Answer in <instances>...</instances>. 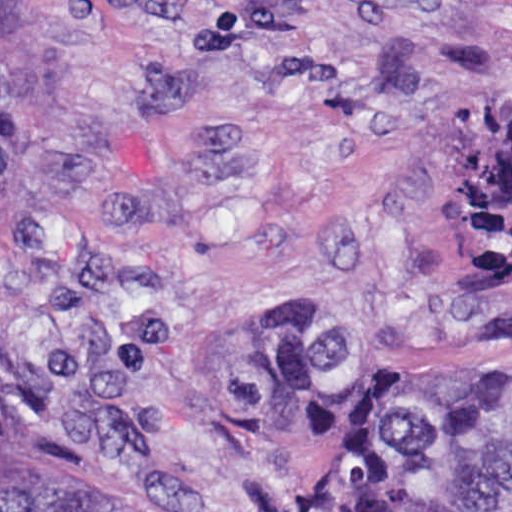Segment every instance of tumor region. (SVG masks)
<instances>
[{
  "mask_svg": "<svg viewBox=\"0 0 512 512\" xmlns=\"http://www.w3.org/2000/svg\"><path fill=\"white\" fill-rule=\"evenodd\" d=\"M466 266L485 309L512 294V98L459 120ZM230 416L274 439L325 421L317 512H512V360L428 377L375 339L257 309L217 344ZM1 512H116L63 457L3 437Z\"/></svg>",
  "mask_w": 512,
  "mask_h": 512,
  "instance_id": "1",
  "label": "tumor region"
}]
</instances>
